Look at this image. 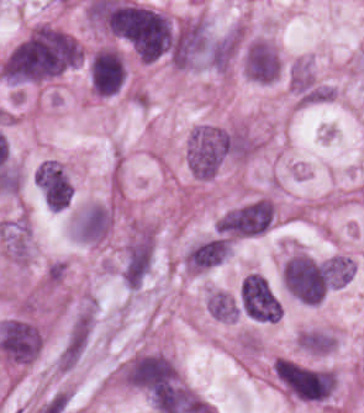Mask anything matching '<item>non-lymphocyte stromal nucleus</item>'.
I'll list each match as a JSON object with an SVG mask.
<instances>
[{
  "label": "non-lymphocyte stromal nucleus",
  "instance_id": "non-lymphocyte-stromal-nucleus-1",
  "mask_svg": "<svg viewBox=\"0 0 364 413\" xmlns=\"http://www.w3.org/2000/svg\"><path fill=\"white\" fill-rule=\"evenodd\" d=\"M90 332V313L84 312L75 318L67 332L58 357L59 367H69L73 364Z\"/></svg>",
  "mask_w": 364,
  "mask_h": 413
}]
</instances>
